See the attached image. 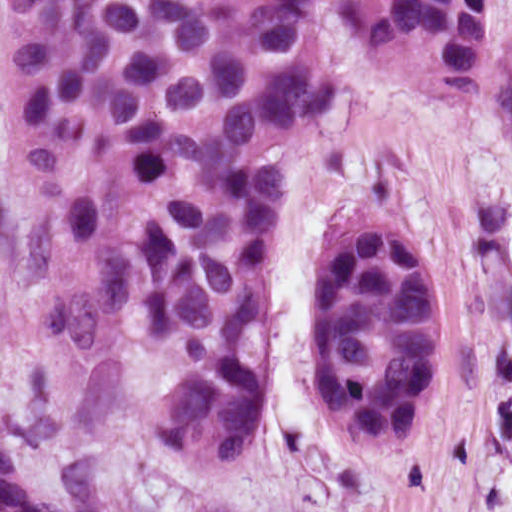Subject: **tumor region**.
<instances>
[{
    "label": "tumor region",
    "instance_id": "tumor-region-1",
    "mask_svg": "<svg viewBox=\"0 0 512 512\" xmlns=\"http://www.w3.org/2000/svg\"><path fill=\"white\" fill-rule=\"evenodd\" d=\"M369 64L476 99L480 0H0L25 262L76 361L157 449L235 468L267 379L269 220L340 95L324 8ZM443 361L430 238L371 211L309 294V385L357 453L424 435ZM0 512L53 502L0 438ZM202 512H240L218 505Z\"/></svg>",
    "mask_w": 512,
    "mask_h": 512
}]
</instances>
